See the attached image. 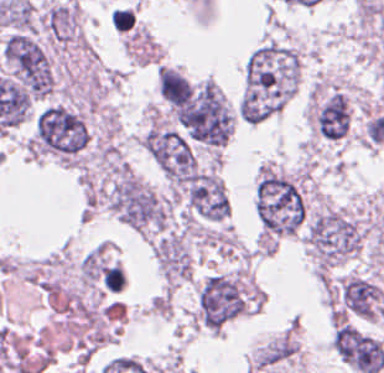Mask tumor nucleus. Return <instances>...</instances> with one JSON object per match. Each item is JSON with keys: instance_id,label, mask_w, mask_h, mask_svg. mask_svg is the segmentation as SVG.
Returning a JSON list of instances; mask_svg holds the SVG:
<instances>
[{"instance_id": "3", "label": "tumor nucleus", "mask_w": 384, "mask_h": 373, "mask_svg": "<svg viewBox=\"0 0 384 373\" xmlns=\"http://www.w3.org/2000/svg\"><path fill=\"white\" fill-rule=\"evenodd\" d=\"M88 138L84 116L76 108L54 102L36 113L30 150L62 160H75Z\"/></svg>"}, {"instance_id": "1", "label": "tumor nucleus", "mask_w": 384, "mask_h": 373, "mask_svg": "<svg viewBox=\"0 0 384 373\" xmlns=\"http://www.w3.org/2000/svg\"><path fill=\"white\" fill-rule=\"evenodd\" d=\"M255 204L264 233L290 234L305 218V200L300 183L272 165L262 167Z\"/></svg>"}, {"instance_id": "2", "label": "tumor nucleus", "mask_w": 384, "mask_h": 373, "mask_svg": "<svg viewBox=\"0 0 384 373\" xmlns=\"http://www.w3.org/2000/svg\"><path fill=\"white\" fill-rule=\"evenodd\" d=\"M362 228L341 208L324 207L308 221L305 245L317 271H326L360 248Z\"/></svg>"}, {"instance_id": "4", "label": "tumor nucleus", "mask_w": 384, "mask_h": 373, "mask_svg": "<svg viewBox=\"0 0 384 373\" xmlns=\"http://www.w3.org/2000/svg\"><path fill=\"white\" fill-rule=\"evenodd\" d=\"M4 60L18 86L29 96L51 92L55 77L47 52L25 31H12L0 46Z\"/></svg>"}, {"instance_id": "8", "label": "tumor nucleus", "mask_w": 384, "mask_h": 373, "mask_svg": "<svg viewBox=\"0 0 384 373\" xmlns=\"http://www.w3.org/2000/svg\"><path fill=\"white\" fill-rule=\"evenodd\" d=\"M336 307L360 317L383 315L380 290L362 275L346 274L334 288Z\"/></svg>"}, {"instance_id": "11", "label": "tumor nucleus", "mask_w": 384, "mask_h": 373, "mask_svg": "<svg viewBox=\"0 0 384 373\" xmlns=\"http://www.w3.org/2000/svg\"><path fill=\"white\" fill-rule=\"evenodd\" d=\"M158 86L163 98L174 104L185 103L192 95L188 81L173 67L159 66Z\"/></svg>"}, {"instance_id": "7", "label": "tumor nucleus", "mask_w": 384, "mask_h": 373, "mask_svg": "<svg viewBox=\"0 0 384 373\" xmlns=\"http://www.w3.org/2000/svg\"><path fill=\"white\" fill-rule=\"evenodd\" d=\"M331 343L339 357L356 373H377L384 364L382 342L351 324L335 326Z\"/></svg>"}, {"instance_id": "6", "label": "tumor nucleus", "mask_w": 384, "mask_h": 373, "mask_svg": "<svg viewBox=\"0 0 384 373\" xmlns=\"http://www.w3.org/2000/svg\"><path fill=\"white\" fill-rule=\"evenodd\" d=\"M196 139L222 143L231 126V112L215 83L203 82L175 109Z\"/></svg>"}, {"instance_id": "5", "label": "tumor nucleus", "mask_w": 384, "mask_h": 373, "mask_svg": "<svg viewBox=\"0 0 384 373\" xmlns=\"http://www.w3.org/2000/svg\"><path fill=\"white\" fill-rule=\"evenodd\" d=\"M247 307V293L238 274L212 273L198 286L195 317L203 327L220 330Z\"/></svg>"}, {"instance_id": "10", "label": "tumor nucleus", "mask_w": 384, "mask_h": 373, "mask_svg": "<svg viewBox=\"0 0 384 373\" xmlns=\"http://www.w3.org/2000/svg\"><path fill=\"white\" fill-rule=\"evenodd\" d=\"M41 22L56 42H76L80 37L77 5L73 0L52 4L41 15Z\"/></svg>"}, {"instance_id": "9", "label": "tumor nucleus", "mask_w": 384, "mask_h": 373, "mask_svg": "<svg viewBox=\"0 0 384 373\" xmlns=\"http://www.w3.org/2000/svg\"><path fill=\"white\" fill-rule=\"evenodd\" d=\"M314 124L319 136L337 141L344 137L350 125V103L345 92L331 88L315 100Z\"/></svg>"}]
</instances>
